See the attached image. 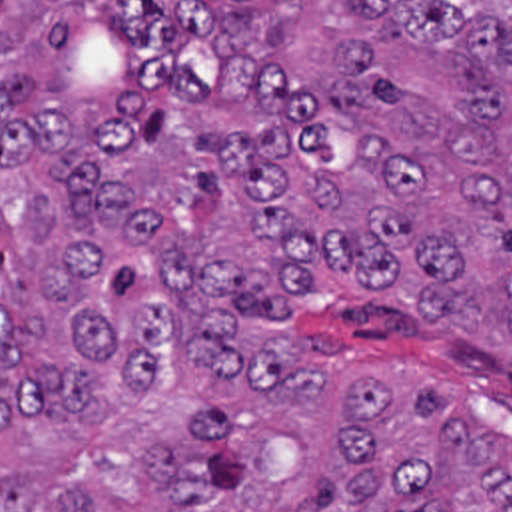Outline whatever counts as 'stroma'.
Instances as JSON below:
<instances>
[{
    "instance_id": "1",
    "label": "stroma",
    "mask_w": 512,
    "mask_h": 512,
    "mask_svg": "<svg viewBox=\"0 0 512 512\" xmlns=\"http://www.w3.org/2000/svg\"><path fill=\"white\" fill-rule=\"evenodd\" d=\"M285 332L287 352L347 354L435 372L461 390L479 420L512 430V370L439 324L407 316L391 304L303 298Z\"/></svg>"
}]
</instances>
